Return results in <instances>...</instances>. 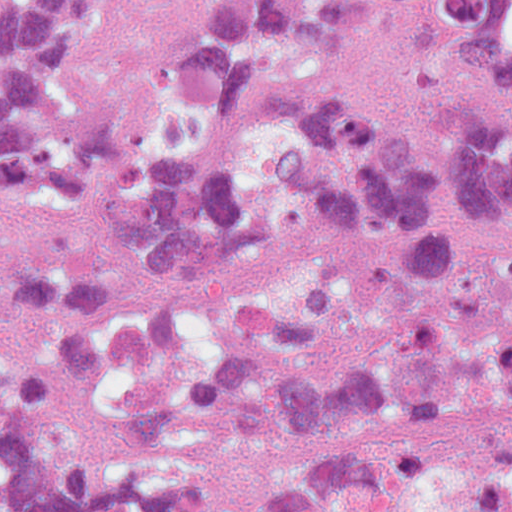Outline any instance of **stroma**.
<instances>
[{
  "label": "stroma",
  "mask_w": 512,
  "mask_h": 512,
  "mask_svg": "<svg viewBox=\"0 0 512 512\" xmlns=\"http://www.w3.org/2000/svg\"><path fill=\"white\" fill-rule=\"evenodd\" d=\"M171 0H84L66 51L49 63L69 102V125L132 121L146 89V39Z\"/></svg>",
  "instance_id": "obj_1"
}]
</instances>
